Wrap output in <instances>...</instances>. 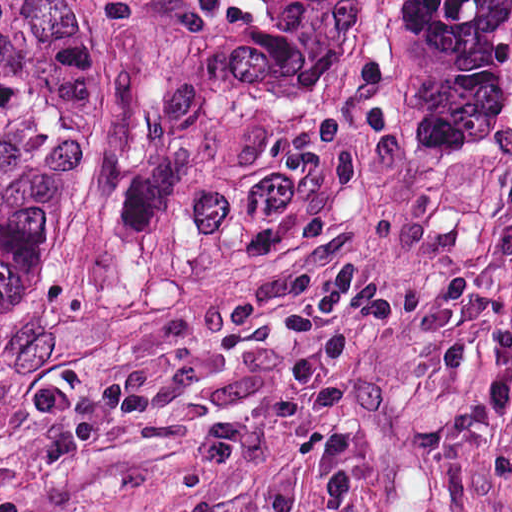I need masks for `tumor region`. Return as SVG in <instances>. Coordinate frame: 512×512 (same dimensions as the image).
<instances>
[{"label":"tumor region","instance_id":"obj_1","mask_svg":"<svg viewBox=\"0 0 512 512\" xmlns=\"http://www.w3.org/2000/svg\"><path fill=\"white\" fill-rule=\"evenodd\" d=\"M134 34L90 190L105 251L143 236L179 110L338 132L360 95L365 0H129ZM74 4L0 0V310L39 282Z\"/></svg>","mask_w":512,"mask_h":512}]
</instances>
